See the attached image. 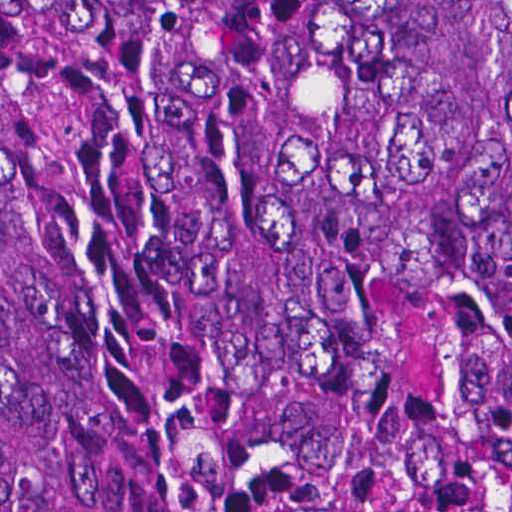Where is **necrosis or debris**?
<instances>
[{
	"label": "necrosis or debris",
	"mask_w": 512,
	"mask_h": 512,
	"mask_svg": "<svg viewBox=\"0 0 512 512\" xmlns=\"http://www.w3.org/2000/svg\"><path fill=\"white\" fill-rule=\"evenodd\" d=\"M234 512H512L472 406L456 304L418 284L376 307V412L348 456L243 481Z\"/></svg>",
	"instance_id": "obj_1"
}]
</instances>
